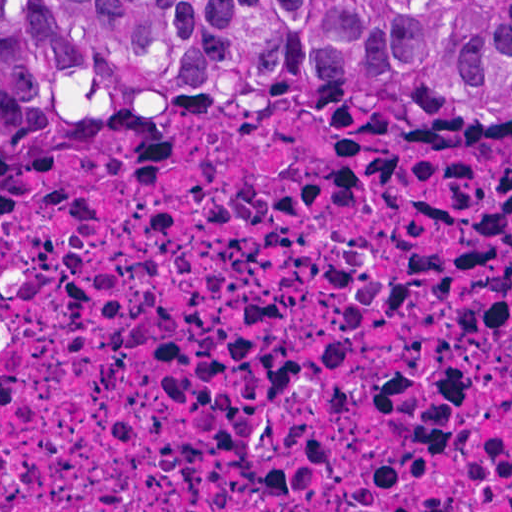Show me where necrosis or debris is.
<instances>
[{
  "mask_svg": "<svg viewBox=\"0 0 512 512\" xmlns=\"http://www.w3.org/2000/svg\"><path fill=\"white\" fill-rule=\"evenodd\" d=\"M0 512H512V126L104 119L0 185Z\"/></svg>",
  "mask_w": 512,
  "mask_h": 512,
  "instance_id": "4bbe7bcc",
  "label": "necrosis or debris"
}]
</instances>
